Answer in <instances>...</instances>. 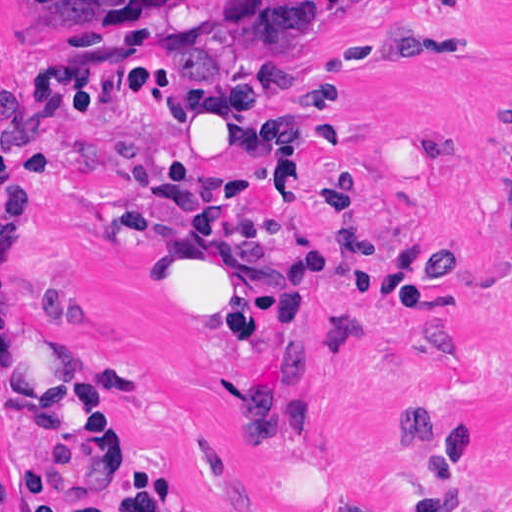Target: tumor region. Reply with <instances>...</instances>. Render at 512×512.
Returning <instances> with one entry per match:
<instances>
[{"label": "tumor region", "mask_w": 512, "mask_h": 512, "mask_svg": "<svg viewBox=\"0 0 512 512\" xmlns=\"http://www.w3.org/2000/svg\"><path fill=\"white\" fill-rule=\"evenodd\" d=\"M40 13L2 36L21 50L57 27L90 22L104 6L124 0H30ZM338 0H208L187 18L185 73L237 75L316 27Z\"/></svg>", "instance_id": "e687c5a6"}]
</instances>
